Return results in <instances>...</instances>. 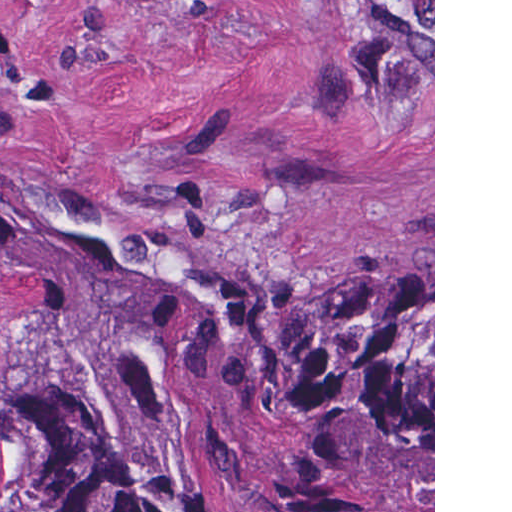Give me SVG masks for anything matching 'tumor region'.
I'll use <instances>...</instances> for the list:
<instances>
[{"mask_svg":"<svg viewBox=\"0 0 512 512\" xmlns=\"http://www.w3.org/2000/svg\"><path fill=\"white\" fill-rule=\"evenodd\" d=\"M0 512H433V268L287 293L0 190Z\"/></svg>","mask_w":512,"mask_h":512,"instance_id":"1","label":"tumor region"}]
</instances>
